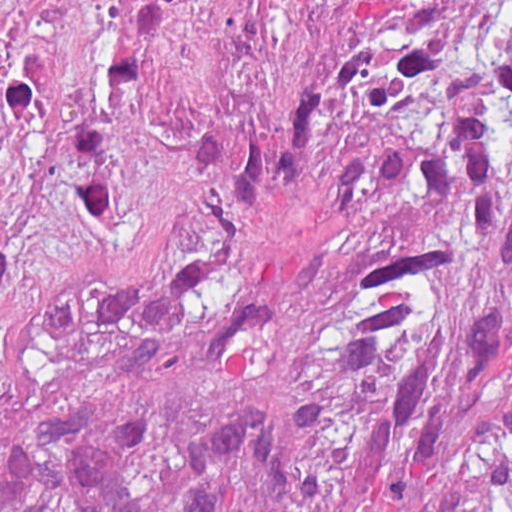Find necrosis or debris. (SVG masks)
<instances>
[{
	"label": "necrosis or debris",
	"mask_w": 512,
	"mask_h": 512,
	"mask_svg": "<svg viewBox=\"0 0 512 512\" xmlns=\"http://www.w3.org/2000/svg\"><path fill=\"white\" fill-rule=\"evenodd\" d=\"M509 19L512 0H0V122L167 103L266 129Z\"/></svg>",
	"instance_id": "4bbe7bcc"
}]
</instances>
